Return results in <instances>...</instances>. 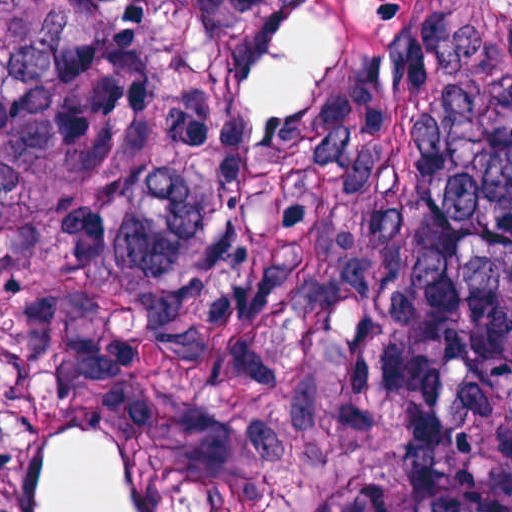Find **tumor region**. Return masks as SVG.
<instances>
[{"label": "tumor region", "instance_id": "1", "mask_svg": "<svg viewBox=\"0 0 512 512\" xmlns=\"http://www.w3.org/2000/svg\"><path fill=\"white\" fill-rule=\"evenodd\" d=\"M0 512H512V0H0Z\"/></svg>", "mask_w": 512, "mask_h": 512}]
</instances>
